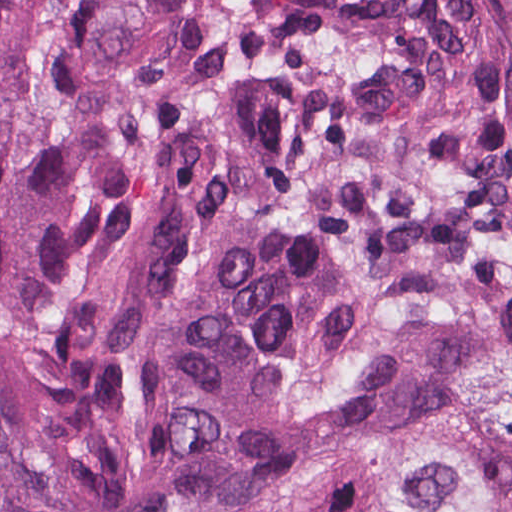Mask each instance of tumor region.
Listing matches in <instances>:
<instances>
[{
    "instance_id": "tumor-region-1",
    "label": "tumor region",
    "mask_w": 512,
    "mask_h": 512,
    "mask_svg": "<svg viewBox=\"0 0 512 512\" xmlns=\"http://www.w3.org/2000/svg\"><path fill=\"white\" fill-rule=\"evenodd\" d=\"M512 512V43L466 0H0V512Z\"/></svg>"
}]
</instances>
